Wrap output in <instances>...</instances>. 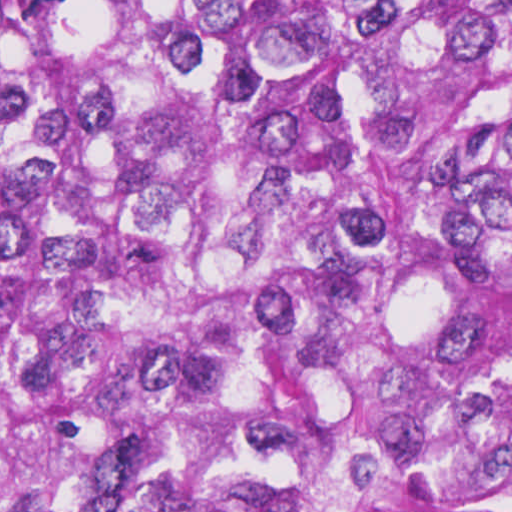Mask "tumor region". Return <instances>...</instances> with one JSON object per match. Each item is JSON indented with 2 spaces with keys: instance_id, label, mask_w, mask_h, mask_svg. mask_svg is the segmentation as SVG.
Listing matches in <instances>:
<instances>
[{
  "instance_id": "tumor-region-1",
  "label": "tumor region",
  "mask_w": 512,
  "mask_h": 512,
  "mask_svg": "<svg viewBox=\"0 0 512 512\" xmlns=\"http://www.w3.org/2000/svg\"><path fill=\"white\" fill-rule=\"evenodd\" d=\"M0 512H512V0H0Z\"/></svg>"
}]
</instances>
